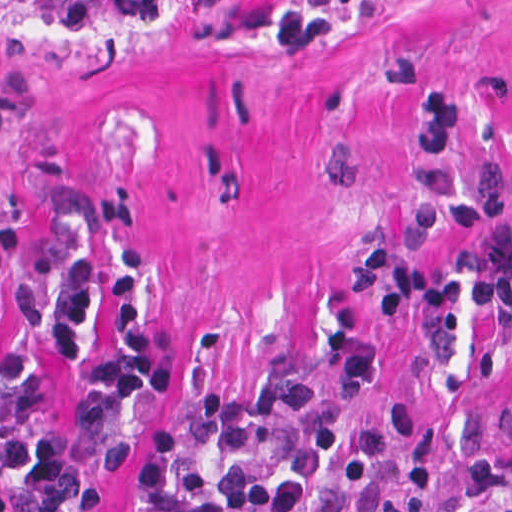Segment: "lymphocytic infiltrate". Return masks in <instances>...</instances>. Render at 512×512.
Listing matches in <instances>:
<instances>
[{
	"mask_svg": "<svg viewBox=\"0 0 512 512\" xmlns=\"http://www.w3.org/2000/svg\"><path fill=\"white\" fill-rule=\"evenodd\" d=\"M215 1L253 15L295 46H314L361 0ZM417 79L425 100L419 158L453 160L462 147V96L448 82ZM415 215L424 230L468 237L453 260L428 263L381 242L360 249L341 273L345 295L378 322L449 308L512 315V172L486 169L480 186L458 190L428 165L415 178ZM0 255L28 269L14 292L24 344L3 341L0 314V470H14L11 485L24 512H96L129 446L131 415L175 378L135 309L137 249L116 280L120 355L93 363L74 410L29 448L47 295L54 348L78 357L91 270L80 256L46 252L18 234L0 237ZM438 451L432 417L405 406H355L316 378H283L257 393H204L160 422L131 512H436L427 479ZM501 508L512 512V495ZM0 512H11L2 499Z\"/></svg>",
	"mask_w": 512,
	"mask_h": 512,
	"instance_id": "f902f5d3",
	"label": "lymphocytic infiltrate"
}]
</instances>
